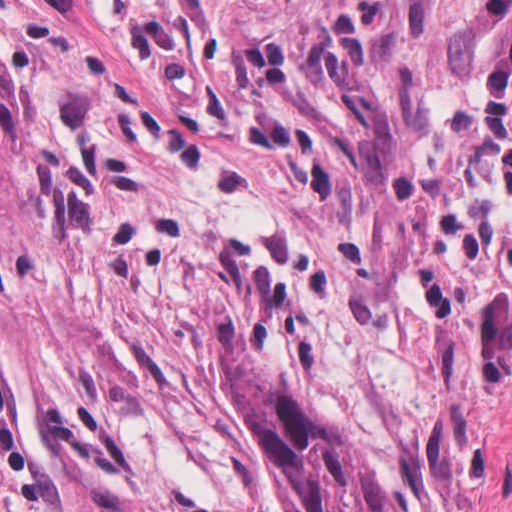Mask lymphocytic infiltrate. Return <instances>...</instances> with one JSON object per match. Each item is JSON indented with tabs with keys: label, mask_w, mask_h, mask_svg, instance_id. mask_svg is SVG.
Listing matches in <instances>:
<instances>
[{
	"label": "lymphocytic infiltrate",
	"mask_w": 512,
	"mask_h": 512,
	"mask_svg": "<svg viewBox=\"0 0 512 512\" xmlns=\"http://www.w3.org/2000/svg\"><path fill=\"white\" fill-rule=\"evenodd\" d=\"M0 512H57V470L34 440L11 390L0 334Z\"/></svg>",
	"instance_id": "obj_1"
}]
</instances>
